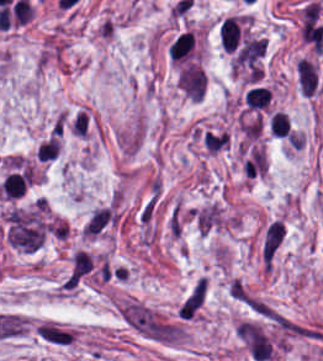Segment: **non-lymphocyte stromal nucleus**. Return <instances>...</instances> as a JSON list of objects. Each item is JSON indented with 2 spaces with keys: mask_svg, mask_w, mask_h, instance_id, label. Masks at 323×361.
Wrapping results in <instances>:
<instances>
[{
  "mask_svg": "<svg viewBox=\"0 0 323 361\" xmlns=\"http://www.w3.org/2000/svg\"><path fill=\"white\" fill-rule=\"evenodd\" d=\"M91 253L77 252L62 284V289H75L82 281Z\"/></svg>",
  "mask_w": 323,
  "mask_h": 361,
  "instance_id": "4",
  "label": "non-lymphocyte stromal nucleus"
},
{
  "mask_svg": "<svg viewBox=\"0 0 323 361\" xmlns=\"http://www.w3.org/2000/svg\"><path fill=\"white\" fill-rule=\"evenodd\" d=\"M297 84L301 95L313 93L314 82L312 66L303 59H299L296 63Z\"/></svg>",
  "mask_w": 323,
  "mask_h": 361,
  "instance_id": "5",
  "label": "non-lymphocyte stromal nucleus"
},
{
  "mask_svg": "<svg viewBox=\"0 0 323 361\" xmlns=\"http://www.w3.org/2000/svg\"><path fill=\"white\" fill-rule=\"evenodd\" d=\"M206 296L204 279H197L178 308L181 319H195Z\"/></svg>",
  "mask_w": 323,
  "mask_h": 361,
  "instance_id": "3",
  "label": "non-lymphocyte stromal nucleus"
},
{
  "mask_svg": "<svg viewBox=\"0 0 323 361\" xmlns=\"http://www.w3.org/2000/svg\"><path fill=\"white\" fill-rule=\"evenodd\" d=\"M284 236L285 227L280 219H273L268 222L260 243L261 267L270 268Z\"/></svg>",
  "mask_w": 323,
  "mask_h": 361,
  "instance_id": "2",
  "label": "non-lymphocyte stromal nucleus"
},
{
  "mask_svg": "<svg viewBox=\"0 0 323 361\" xmlns=\"http://www.w3.org/2000/svg\"><path fill=\"white\" fill-rule=\"evenodd\" d=\"M123 326L146 341L177 347L186 341V329L177 320L137 299H123L117 304Z\"/></svg>",
  "mask_w": 323,
  "mask_h": 361,
  "instance_id": "1",
  "label": "non-lymphocyte stromal nucleus"
},
{
  "mask_svg": "<svg viewBox=\"0 0 323 361\" xmlns=\"http://www.w3.org/2000/svg\"><path fill=\"white\" fill-rule=\"evenodd\" d=\"M34 335H39V336H43V337H48V338H52V339L70 342V343L75 340V334L62 332V331H58V330H54V329H50V328H45V327H41V326H37V325L34 326Z\"/></svg>",
  "mask_w": 323,
  "mask_h": 361,
  "instance_id": "6",
  "label": "non-lymphocyte stromal nucleus"
}]
</instances>
